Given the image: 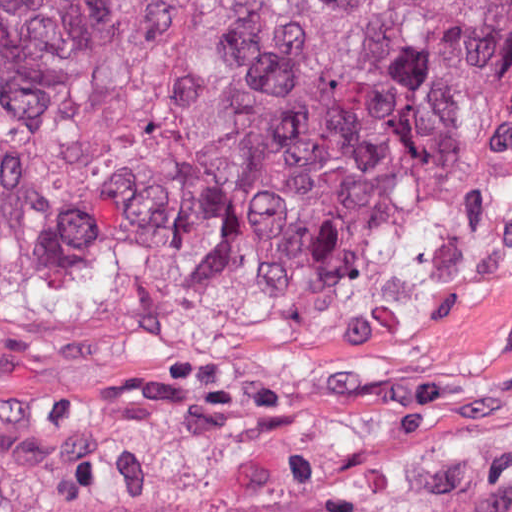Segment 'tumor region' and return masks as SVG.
Segmentation results:
<instances>
[{
    "instance_id": "obj_1",
    "label": "tumor region",
    "mask_w": 512,
    "mask_h": 512,
    "mask_svg": "<svg viewBox=\"0 0 512 512\" xmlns=\"http://www.w3.org/2000/svg\"><path fill=\"white\" fill-rule=\"evenodd\" d=\"M209 239L377 298L512 268V0H0V291L84 308ZM308 512H512V446Z\"/></svg>"
}]
</instances>
